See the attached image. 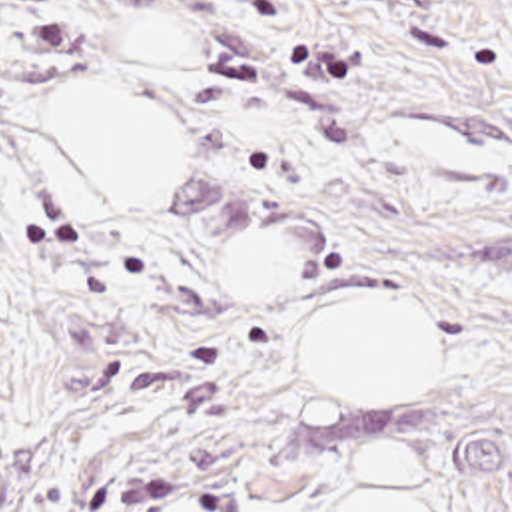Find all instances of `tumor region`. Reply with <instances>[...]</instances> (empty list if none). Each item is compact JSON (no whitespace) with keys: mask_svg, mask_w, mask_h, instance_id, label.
Returning a JSON list of instances; mask_svg holds the SVG:
<instances>
[{"mask_svg":"<svg viewBox=\"0 0 512 512\" xmlns=\"http://www.w3.org/2000/svg\"><path fill=\"white\" fill-rule=\"evenodd\" d=\"M0 512H19V480L11 466L7 442L0 438Z\"/></svg>","mask_w":512,"mask_h":512,"instance_id":"1","label":"tumor region"}]
</instances>
